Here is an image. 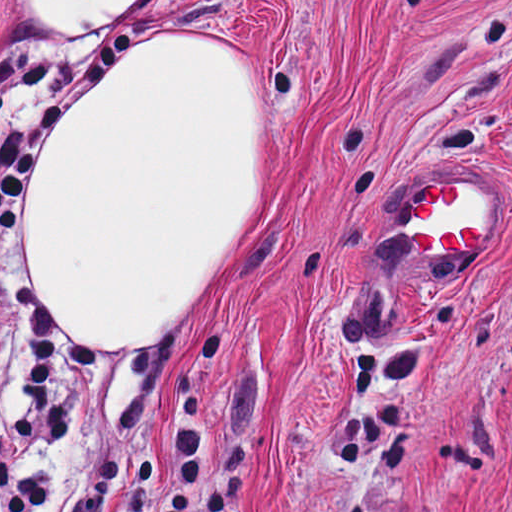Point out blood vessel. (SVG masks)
<instances>
[{"label": "blood vessel", "mask_w": 512, "mask_h": 512, "mask_svg": "<svg viewBox=\"0 0 512 512\" xmlns=\"http://www.w3.org/2000/svg\"><path fill=\"white\" fill-rule=\"evenodd\" d=\"M421 260H471L492 233V180L453 179L411 200L399 226Z\"/></svg>", "instance_id": "obj_1"}]
</instances>
